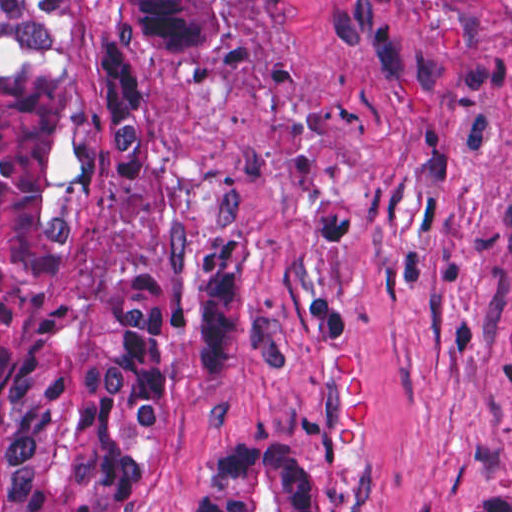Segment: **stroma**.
I'll list each match as a JSON object with an SVG mask.
<instances>
[{"label":"stroma","instance_id":"stroma-1","mask_svg":"<svg viewBox=\"0 0 512 512\" xmlns=\"http://www.w3.org/2000/svg\"><path fill=\"white\" fill-rule=\"evenodd\" d=\"M139 92L88 255L234 256L253 285V353L173 407L141 512H185V463L245 431L302 448L323 512L512 489V3L247 0L226 50L148 61Z\"/></svg>","mask_w":512,"mask_h":512}]
</instances>
